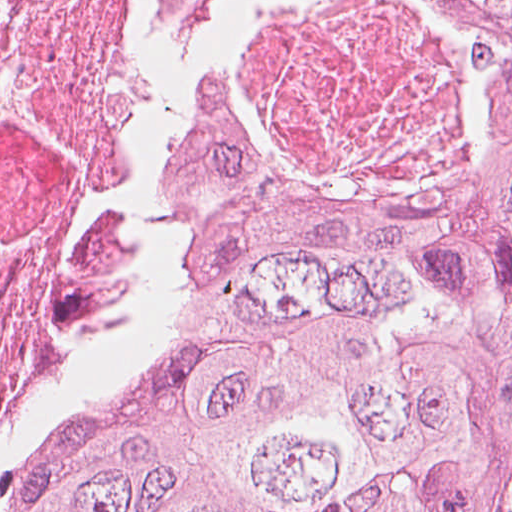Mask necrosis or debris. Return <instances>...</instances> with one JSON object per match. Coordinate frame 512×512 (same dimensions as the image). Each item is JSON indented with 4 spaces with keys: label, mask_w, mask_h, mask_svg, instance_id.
Instances as JSON below:
<instances>
[{
    "label": "necrosis or debris",
    "mask_w": 512,
    "mask_h": 512,
    "mask_svg": "<svg viewBox=\"0 0 512 512\" xmlns=\"http://www.w3.org/2000/svg\"><path fill=\"white\" fill-rule=\"evenodd\" d=\"M419 0L257 13L231 85L262 143L334 190L413 209L477 127ZM167 127L139 0H0V482L126 347L169 257L144 204Z\"/></svg>",
    "instance_id": "obj_1"
}]
</instances>
